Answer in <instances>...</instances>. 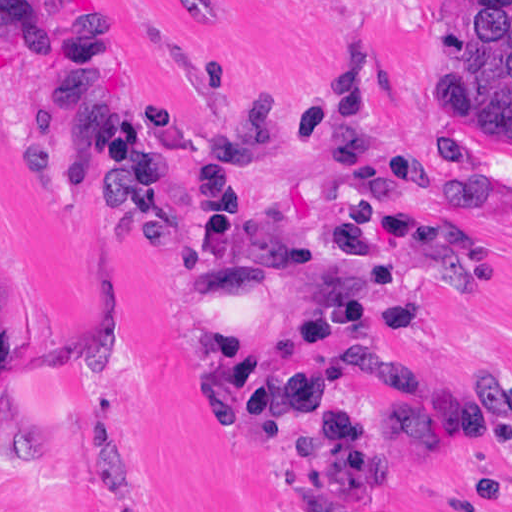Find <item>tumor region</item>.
Wrapping results in <instances>:
<instances>
[{"label": "tumor region", "mask_w": 512, "mask_h": 512, "mask_svg": "<svg viewBox=\"0 0 512 512\" xmlns=\"http://www.w3.org/2000/svg\"><path fill=\"white\" fill-rule=\"evenodd\" d=\"M441 64L456 101L512 132V0H453Z\"/></svg>", "instance_id": "tumor-region-1"}]
</instances>
